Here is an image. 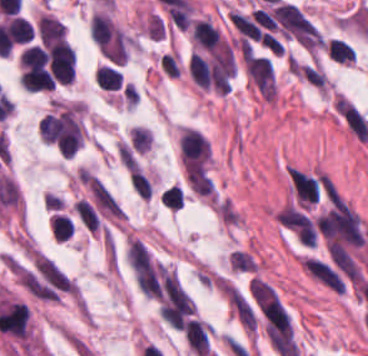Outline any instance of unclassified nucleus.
Returning a JSON list of instances; mask_svg holds the SVG:
<instances>
[{"label":"unclassified nucleus","mask_w":368,"mask_h":356,"mask_svg":"<svg viewBox=\"0 0 368 356\" xmlns=\"http://www.w3.org/2000/svg\"><path fill=\"white\" fill-rule=\"evenodd\" d=\"M302 266L306 272L327 287L343 293L342 278L325 262L304 258Z\"/></svg>","instance_id":"unclassified-nucleus-1"}]
</instances>
